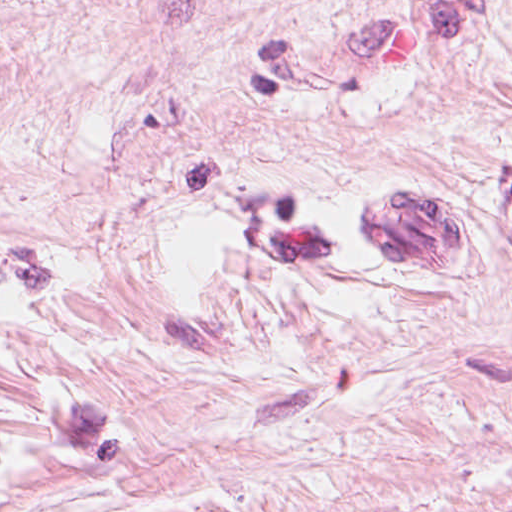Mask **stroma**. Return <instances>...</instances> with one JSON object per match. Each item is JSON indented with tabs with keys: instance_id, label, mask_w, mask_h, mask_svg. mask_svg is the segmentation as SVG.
<instances>
[{
	"instance_id": "obj_1",
	"label": "stroma",
	"mask_w": 512,
	"mask_h": 512,
	"mask_svg": "<svg viewBox=\"0 0 512 512\" xmlns=\"http://www.w3.org/2000/svg\"><path fill=\"white\" fill-rule=\"evenodd\" d=\"M0 512H512V0H0Z\"/></svg>"
}]
</instances>
